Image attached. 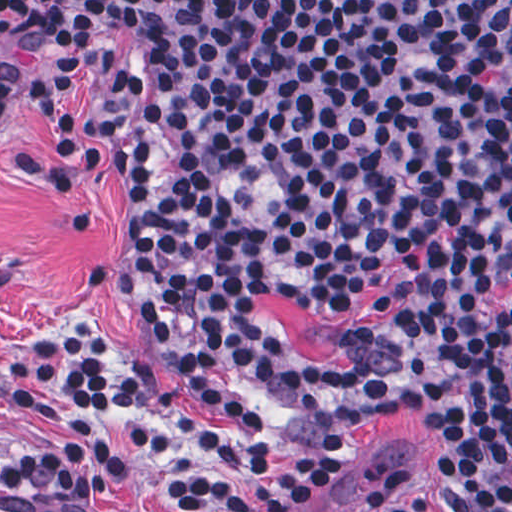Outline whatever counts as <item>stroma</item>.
Here are the masks:
<instances>
[{"instance_id": "obj_1", "label": "stroma", "mask_w": 512, "mask_h": 512, "mask_svg": "<svg viewBox=\"0 0 512 512\" xmlns=\"http://www.w3.org/2000/svg\"><path fill=\"white\" fill-rule=\"evenodd\" d=\"M82 75L68 88L75 134V167L63 209L47 186L16 177L4 165L10 147L32 157L50 156V137L33 98L12 97L0 122V355L30 342L63 314H86L105 332L124 364L135 351L156 356L170 371L176 404L193 421L231 436H246L284 450L344 458L352 467L334 494L311 512H353L378 474L400 468L410 475L433 512H445L428 464V432L417 388L475 363L494 368V346L505 327L392 394L357 400L300 424L274 429L232 411V418L200 402L191 371L156 337L119 277L111 232L127 214L128 142L110 119L113 77ZM397 278L381 276L365 286L343 313L298 304L266 293L257 306L282 329L288 342L316 364H338V336L377 317L375 297ZM61 411H22L0 403V453L27 460L65 432ZM101 427L124 463L111 498L138 512H154L145 494L150 484L200 472L197 452L186 448L168 458L136 447L115 413ZM0 512H70L21 493L0 489Z\"/></svg>"}]
</instances>
